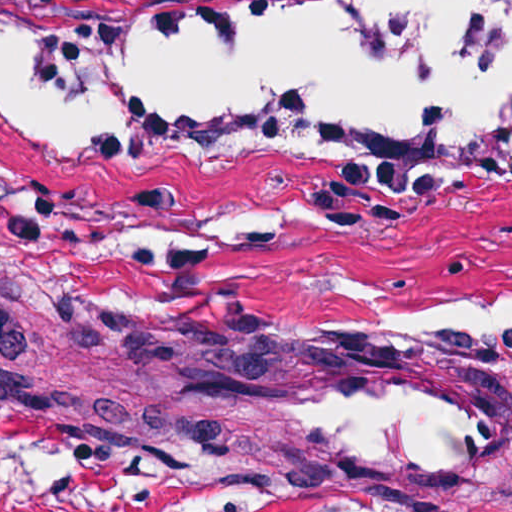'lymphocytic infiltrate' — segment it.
<instances>
[{
    "mask_svg": "<svg viewBox=\"0 0 512 512\" xmlns=\"http://www.w3.org/2000/svg\"><path fill=\"white\" fill-rule=\"evenodd\" d=\"M140 0H0V6L22 16H58L81 5H112Z\"/></svg>",
    "mask_w": 512,
    "mask_h": 512,
    "instance_id": "obj_1",
    "label": "lymphocytic infiltrate"
}]
</instances>
